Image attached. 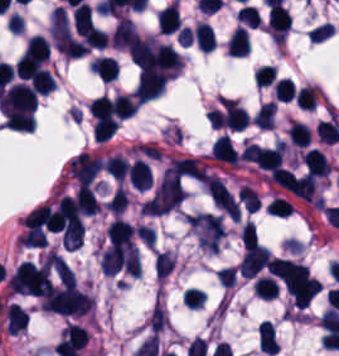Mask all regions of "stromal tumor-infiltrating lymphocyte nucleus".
<instances>
[{"label":"stromal tumor-infiltrating lymphocyte nucleus","instance_id":"7eef579d","mask_svg":"<svg viewBox=\"0 0 339 356\" xmlns=\"http://www.w3.org/2000/svg\"><path fill=\"white\" fill-rule=\"evenodd\" d=\"M112 101L116 115L122 119L131 116L136 109V101L130 94H116Z\"/></svg>","mask_w":339,"mask_h":356},{"label":"stromal tumor-infiltrating lymphocyte nucleus","instance_id":"52c7bb5b","mask_svg":"<svg viewBox=\"0 0 339 356\" xmlns=\"http://www.w3.org/2000/svg\"><path fill=\"white\" fill-rule=\"evenodd\" d=\"M96 154L80 152L67 162L68 172L76 182H90L102 166Z\"/></svg>","mask_w":339,"mask_h":356},{"label":"stromal tumor-infiltrating lymphocyte nucleus","instance_id":"4245b91a","mask_svg":"<svg viewBox=\"0 0 339 356\" xmlns=\"http://www.w3.org/2000/svg\"><path fill=\"white\" fill-rule=\"evenodd\" d=\"M26 322L27 315L17 303L11 302L5 307L6 331L14 335L26 326Z\"/></svg>","mask_w":339,"mask_h":356},{"label":"stromal tumor-infiltrating lymphocyte nucleus","instance_id":"c26a33f6","mask_svg":"<svg viewBox=\"0 0 339 356\" xmlns=\"http://www.w3.org/2000/svg\"><path fill=\"white\" fill-rule=\"evenodd\" d=\"M286 133L290 143L305 147L309 139L310 129L299 120H292Z\"/></svg>","mask_w":339,"mask_h":356},{"label":"stromal tumor-infiltrating lymphocyte nucleus","instance_id":"abfb95fc","mask_svg":"<svg viewBox=\"0 0 339 356\" xmlns=\"http://www.w3.org/2000/svg\"><path fill=\"white\" fill-rule=\"evenodd\" d=\"M127 179L136 190H143L151 179L150 170L144 159H135L127 170Z\"/></svg>","mask_w":339,"mask_h":356},{"label":"stromal tumor-infiltrating lymphocyte nucleus","instance_id":"4c9ddf68","mask_svg":"<svg viewBox=\"0 0 339 356\" xmlns=\"http://www.w3.org/2000/svg\"><path fill=\"white\" fill-rule=\"evenodd\" d=\"M90 70L102 82H109L116 76L117 64L112 57L98 56Z\"/></svg>","mask_w":339,"mask_h":356},{"label":"stromal tumor-infiltrating lymphocyte nucleus","instance_id":"a0a3295f","mask_svg":"<svg viewBox=\"0 0 339 356\" xmlns=\"http://www.w3.org/2000/svg\"><path fill=\"white\" fill-rule=\"evenodd\" d=\"M238 198L242 203L243 207L251 212L256 210L260 202L256 191L243 185L240 186L238 189Z\"/></svg>","mask_w":339,"mask_h":356},{"label":"stromal tumor-infiltrating lymphocyte nucleus","instance_id":"2a367800","mask_svg":"<svg viewBox=\"0 0 339 356\" xmlns=\"http://www.w3.org/2000/svg\"><path fill=\"white\" fill-rule=\"evenodd\" d=\"M227 49L232 56H245L250 49L248 32L245 27H236L227 40Z\"/></svg>","mask_w":339,"mask_h":356},{"label":"stromal tumor-infiltrating lymphocyte nucleus","instance_id":"4f13568d","mask_svg":"<svg viewBox=\"0 0 339 356\" xmlns=\"http://www.w3.org/2000/svg\"><path fill=\"white\" fill-rule=\"evenodd\" d=\"M316 131L319 140L332 143L339 140V123L337 114L330 113L317 122Z\"/></svg>","mask_w":339,"mask_h":356},{"label":"stromal tumor-infiltrating lymphocyte nucleus","instance_id":"04cf8593","mask_svg":"<svg viewBox=\"0 0 339 356\" xmlns=\"http://www.w3.org/2000/svg\"><path fill=\"white\" fill-rule=\"evenodd\" d=\"M276 103L272 101H264L254 112L251 117L252 123L261 126L262 128H270L273 123Z\"/></svg>","mask_w":339,"mask_h":356},{"label":"stromal tumor-infiltrating lymphocyte nucleus","instance_id":"f3e2335f","mask_svg":"<svg viewBox=\"0 0 339 356\" xmlns=\"http://www.w3.org/2000/svg\"><path fill=\"white\" fill-rule=\"evenodd\" d=\"M76 201L78 210L82 214H96L99 205L98 201L87 182H79L76 189Z\"/></svg>","mask_w":339,"mask_h":356},{"label":"stromal tumor-infiltrating lymphocyte nucleus","instance_id":"bc302bb0","mask_svg":"<svg viewBox=\"0 0 339 356\" xmlns=\"http://www.w3.org/2000/svg\"><path fill=\"white\" fill-rule=\"evenodd\" d=\"M167 75L159 71L141 69L134 88L137 102H145L157 97L163 90Z\"/></svg>","mask_w":339,"mask_h":356},{"label":"stromal tumor-infiltrating lymphocyte nucleus","instance_id":"3c572f05","mask_svg":"<svg viewBox=\"0 0 339 356\" xmlns=\"http://www.w3.org/2000/svg\"><path fill=\"white\" fill-rule=\"evenodd\" d=\"M193 36L194 42L199 49L209 52L212 51L216 44L212 26L204 22H197L193 30Z\"/></svg>","mask_w":339,"mask_h":356},{"label":"stromal tumor-infiltrating lymphocyte nucleus","instance_id":"e9af9c67","mask_svg":"<svg viewBox=\"0 0 339 356\" xmlns=\"http://www.w3.org/2000/svg\"><path fill=\"white\" fill-rule=\"evenodd\" d=\"M29 86L39 95H46L54 89L55 84L49 73L45 70H38L30 77Z\"/></svg>","mask_w":339,"mask_h":356},{"label":"stromal tumor-infiltrating lymphocyte nucleus","instance_id":"782c7336","mask_svg":"<svg viewBox=\"0 0 339 356\" xmlns=\"http://www.w3.org/2000/svg\"><path fill=\"white\" fill-rule=\"evenodd\" d=\"M102 164L106 172L120 181L125 176L128 166L126 159L120 154H112L106 157Z\"/></svg>","mask_w":339,"mask_h":356},{"label":"stromal tumor-infiltrating lymphocyte nucleus","instance_id":"3290ff9b","mask_svg":"<svg viewBox=\"0 0 339 356\" xmlns=\"http://www.w3.org/2000/svg\"><path fill=\"white\" fill-rule=\"evenodd\" d=\"M2 102L4 105L34 113L36 94L25 84H11L5 92Z\"/></svg>","mask_w":339,"mask_h":356},{"label":"stromal tumor-infiltrating lymphocyte nucleus","instance_id":"2e467ee5","mask_svg":"<svg viewBox=\"0 0 339 356\" xmlns=\"http://www.w3.org/2000/svg\"><path fill=\"white\" fill-rule=\"evenodd\" d=\"M252 289L257 297L272 298L276 293L275 281L269 274H261L252 283Z\"/></svg>","mask_w":339,"mask_h":356},{"label":"stromal tumor-infiltrating lymphocyte nucleus","instance_id":"9e4306bb","mask_svg":"<svg viewBox=\"0 0 339 356\" xmlns=\"http://www.w3.org/2000/svg\"><path fill=\"white\" fill-rule=\"evenodd\" d=\"M319 89L310 85L299 86L293 94L298 109L311 110L319 96Z\"/></svg>","mask_w":339,"mask_h":356},{"label":"stromal tumor-infiltrating lymphocyte nucleus","instance_id":"4803ca6d","mask_svg":"<svg viewBox=\"0 0 339 356\" xmlns=\"http://www.w3.org/2000/svg\"><path fill=\"white\" fill-rule=\"evenodd\" d=\"M302 160L305 171L313 176L325 177L329 173L323 154L314 147L304 152Z\"/></svg>","mask_w":339,"mask_h":356},{"label":"stromal tumor-infiltrating lymphocyte nucleus","instance_id":"cac63f63","mask_svg":"<svg viewBox=\"0 0 339 356\" xmlns=\"http://www.w3.org/2000/svg\"><path fill=\"white\" fill-rule=\"evenodd\" d=\"M175 258L166 250L156 253L153 269L155 278H163L174 268Z\"/></svg>","mask_w":339,"mask_h":356},{"label":"stromal tumor-infiltrating lymphocyte nucleus","instance_id":"b6af03f8","mask_svg":"<svg viewBox=\"0 0 339 356\" xmlns=\"http://www.w3.org/2000/svg\"><path fill=\"white\" fill-rule=\"evenodd\" d=\"M269 215L287 216L291 211L288 201L280 196H273L266 209Z\"/></svg>","mask_w":339,"mask_h":356},{"label":"stromal tumor-infiltrating lymphocyte nucleus","instance_id":"6c763739","mask_svg":"<svg viewBox=\"0 0 339 356\" xmlns=\"http://www.w3.org/2000/svg\"><path fill=\"white\" fill-rule=\"evenodd\" d=\"M242 249H250L256 242V234L254 226L249 221H245L241 229L238 231Z\"/></svg>","mask_w":339,"mask_h":356},{"label":"stromal tumor-infiltrating lymphocyte nucleus","instance_id":"42bb06b2","mask_svg":"<svg viewBox=\"0 0 339 356\" xmlns=\"http://www.w3.org/2000/svg\"><path fill=\"white\" fill-rule=\"evenodd\" d=\"M86 48H103L106 44L107 34L101 28L89 25L77 31Z\"/></svg>","mask_w":339,"mask_h":356},{"label":"stromal tumor-infiltrating lymphocyte nucleus","instance_id":"2761f720","mask_svg":"<svg viewBox=\"0 0 339 356\" xmlns=\"http://www.w3.org/2000/svg\"><path fill=\"white\" fill-rule=\"evenodd\" d=\"M257 339L260 350L269 353H275L277 347V340L274 334V330L269 320H261L257 329Z\"/></svg>","mask_w":339,"mask_h":356},{"label":"stromal tumor-infiltrating lymphocyte nucleus","instance_id":"9ea309e8","mask_svg":"<svg viewBox=\"0 0 339 356\" xmlns=\"http://www.w3.org/2000/svg\"><path fill=\"white\" fill-rule=\"evenodd\" d=\"M209 153L212 157L229 161L232 163L238 162V153L233 146L230 138L224 133L217 136L213 141Z\"/></svg>","mask_w":339,"mask_h":356},{"label":"stromal tumor-infiltrating lymphocyte nucleus","instance_id":"3e0999b9","mask_svg":"<svg viewBox=\"0 0 339 356\" xmlns=\"http://www.w3.org/2000/svg\"><path fill=\"white\" fill-rule=\"evenodd\" d=\"M126 205V195L118 186L105 202V207L115 215H119Z\"/></svg>","mask_w":339,"mask_h":356}]
</instances>
